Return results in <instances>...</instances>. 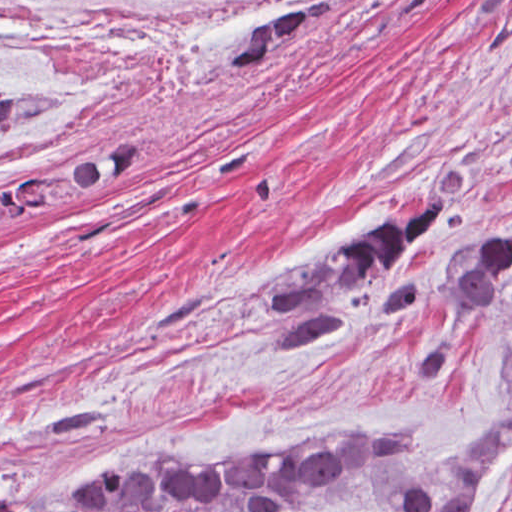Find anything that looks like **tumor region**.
I'll use <instances>...</instances> for the list:
<instances>
[{
  "instance_id": "tumor-region-1",
  "label": "tumor region",
  "mask_w": 512,
  "mask_h": 512,
  "mask_svg": "<svg viewBox=\"0 0 512 512\" xmlns=\"http://www.w3.org/2000/svg\"><path fill=\"white\" fill-rule=\"evenodd\" d=\"M334 9L335 0H305L254 30L230 61L232 75L269 71L299 34ZM58 104L49 94L0 93V129ZM136 161L135 141L58 161L21 206H47L102 190ZM448 210L444 195L418 193L396 212L301 260L268 297L275 353L341 331L346 320L331 310L330 301L385 275ZM510 286L512 221L483 225L451 264L446 282L451 310L472 311ZM414 298L409 280L391 292L386 314L399 315ZM497 358L509 370L502 414L481 435L446 450H433L413 428L346 427L279 448L118 457L92 479L71 512H296L343 501H370L389 512H476L491 472L512 443V330Z\"/></svg>"
}]
</instances>
